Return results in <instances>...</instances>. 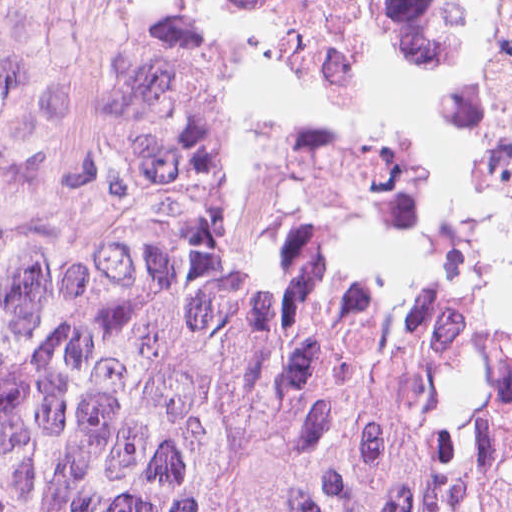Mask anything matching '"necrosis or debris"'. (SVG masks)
Segmentation results:
<instances>
[{
  "label": "necrosis or debris",
  "mask_w": 512,
  "mask_h": 512,
  "mask_svg": "<svg viewBox=\"0 0 512 512\" xmlns=\"http://www.w3.org/2000/svg\"><path fill=\"white\" fill-rule=\"evenodd\" d=\"M179 13H199L305 108L363 208H471L512 55V0H0V114L48 63L128 53Z\"/></svg>",
  "instance_id": "1"
}]
</instances>
